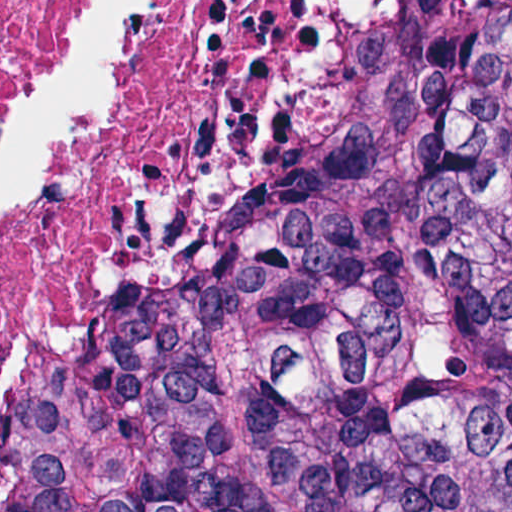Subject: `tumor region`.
I'll return each instance as SVG.
<instances>
[{"label": "tumor region", "instance_id": "obj_1", "mask_svg": "<svg viewBox=\"0 0 512 512\" xmlns=\"http://www.w3.org/2000/svg\"><path fill=\"white\" fill-rule=\"evenodd\" d=\"M105 512H512V0H429L172 318Z\"/></svg>", "mask_w": 512, "mask_h": 512}]
</instances>
